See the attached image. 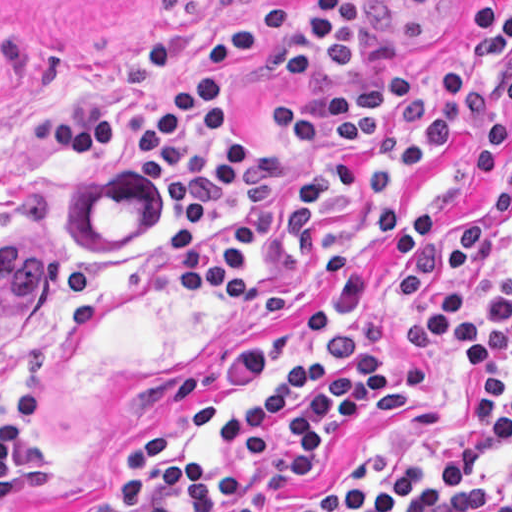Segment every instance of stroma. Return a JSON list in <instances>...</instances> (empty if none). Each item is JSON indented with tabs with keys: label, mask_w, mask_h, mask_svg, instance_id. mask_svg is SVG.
<instances>
[{
	"label": "stroma",
	"mask_w": 512,
	"mask_h": 512,
	"mask_svg": "<svg viewBox=\"0 0 512 512\" xmlns=\"http://www.w3.org/2000/svg\"><path fill=\"white\" fill-rule=\"evenodd\" d=\"M268 1L0 0V232L32 227L55 246V280L43 308L0 355V418L36 375L45 414L33 435L48 451V472L22 497L1 500L0 512H76L110 495L122 481L130 444L157 423L173 431L168 459L256 482L251 512H283L317 491L421 466L464 429L476 367L462 366L443 341L416 356L402 353V335L445 277L468 287V317L477 324L508 286L512 104L499 74L489 81L506 140L499 176L474 175L457 134L396 205V219L404 220L438 210L444 236L441 272L397 314L391 256L366 234L340 288H311L310 261L290 268L282 278L298 298L280 318H243L209 291L183 300L162 250L167 228L181 224L166 196L97 152L37 148L28 137L30 108L90 92L116 96L127 120H140L157 75L136 63L135 37L171 32L180 70L201 78L208 37ZM487 1L495 17L512 11V0ZM470 4L428 11L406 0H366V43L351 71L328 81H279L265 61H252L234 76L229 107L256 151L269 155L275 113L294 98L412 69L431 86L446 66L472 69ZM343 324H362L364 350L397 366L403 389L360 405L323 455L294 474L279 467L282 453L245 462V449L221 444L217 418ZM511 474L512 445L484 477L496 483Z\"/></svg>",
	"instance_id": "stroma-1"
}]
</instances>
